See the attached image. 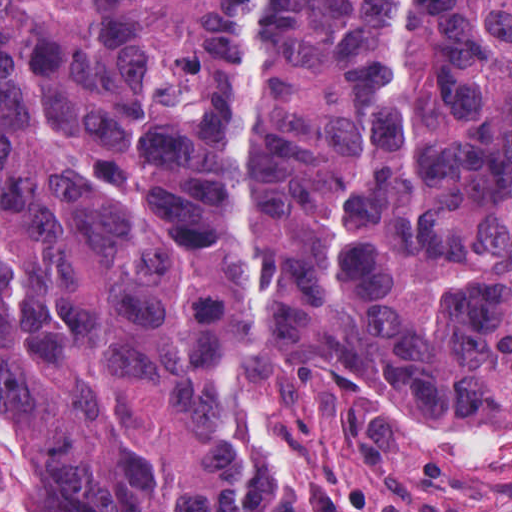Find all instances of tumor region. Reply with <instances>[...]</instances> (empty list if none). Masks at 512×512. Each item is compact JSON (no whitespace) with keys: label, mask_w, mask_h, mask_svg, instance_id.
Listing matches in <instances>:
<instances>
[{"label":"tumor region","mask_w":512,"mask_h":512,"mask_svg":"<svg viewBox=\"0 0 512 512\" xmlns=\"http://www.w3.org/2000/svg\"><path fill=\"white\" fill-rule=\"evenodd\" d=\"M512 416V0H0L24 512H234L236 339Z\"/></svg>","instance_id":"tumor-region-1"}]
</instances>
